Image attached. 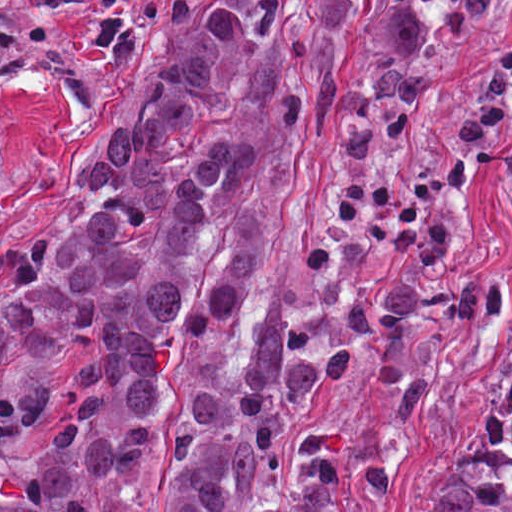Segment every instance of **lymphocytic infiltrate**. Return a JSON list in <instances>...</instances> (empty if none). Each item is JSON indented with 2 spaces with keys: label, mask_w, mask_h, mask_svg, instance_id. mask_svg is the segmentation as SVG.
<instances>
[{
  "label": "lymphocytic infiltrate",
  "mask_w": 512,
  "mask_h": 512,
  "mask_svg": "<svg viewBox=\"0 0 512 512\" xmlns=\"http://www.w3.org/2000/svg\"><path fill=\"white\" fill-rule=\"evenodd\" d=\"M512 129V74L488 68L469 80L441 157L399 168H342L327 177L333 226L302 252L313 279L359 268L366 254L397 248L421 267L456 269L453 189L487 140Z\"/></svg>",
  "instance_id": "1"
}]
</instances>
